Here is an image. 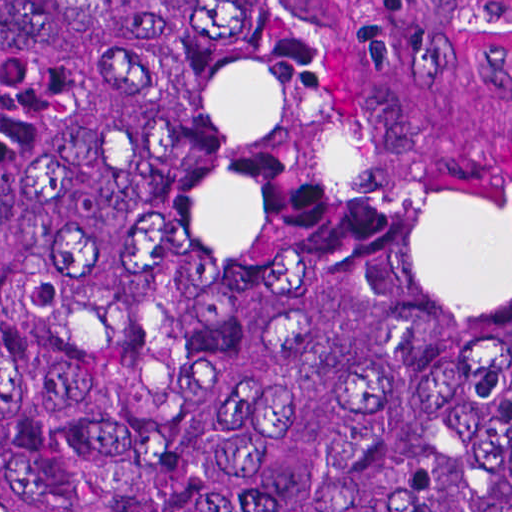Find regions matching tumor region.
<instances>
[{
    "label": "tumor region",
    "mask_w": 512,
    "mask_h": 512,
    "mask_svg": "<svg viewBox=\"0 0 512 512\" xmlns=\"http://www.w3.org/2000/svg\"><path fill=\"white\" fill-rule=\"evenodd\" d=\"M0 512H512V156L362 0H0Z\"/></svg>",
    "instance_id": "tumor-region-1"
}]
</instances>
